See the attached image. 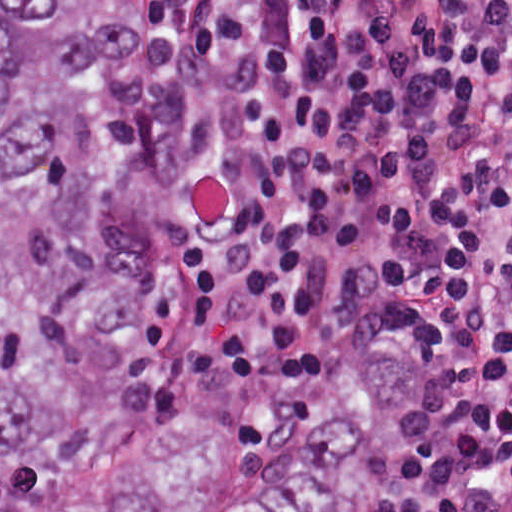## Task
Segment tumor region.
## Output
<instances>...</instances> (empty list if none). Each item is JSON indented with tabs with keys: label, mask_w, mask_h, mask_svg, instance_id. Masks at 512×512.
I'll list each match as a JSON object with an SVG mask.
<instances>
[{
	"label": "tumor region",
	"mask_w": 512,
	"mask_h": 512,
	"mask_svg": "<svg viewBox=\"0 0 512 512\" xmlns=\"http://www.w3.org/2000/svg\"><path fill=\"white\" fill-rule=\"evenodd\" d=\"M175 51L148 0H0V512H398L415 396L226 437L177 365Z\"/></svg>",
	"instance_id": "1"
}]
</instances>
